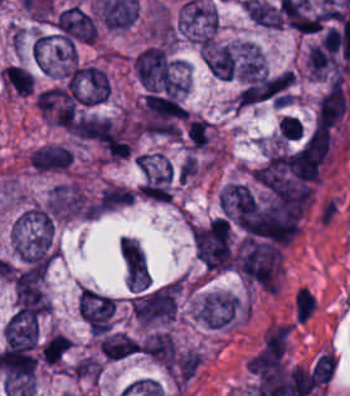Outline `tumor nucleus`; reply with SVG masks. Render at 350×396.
<instances>
[{"label":"tumor nucleus","instance_id":"obj_1","mask_svg":"<svg viewBox=\"0 0 350 396\" xmlns=\"http://www.w3.org/2000/svg\"><path fill=\"white\" fill-rule=\"evenodd\" d=\"M12 247L19 263L30 271H47L55 257L53 222L46 210L30 205L12 227Z\"/></svg>","mask_w":350,"mask_h":396},{"label":"tumor nucleus","instance_id":"obj_8","mask_svg":"<svg viewBox=\"0 0 350 396\" xmlns=\"http://www.w3.org/2000/svg\"><path fill=\"white\" fill-rule=\"evenodd\" d=\"M265 59L258 44L254 41H240L238 77L241 81L251 82L264 75Z\"/></svg>","mask_w":350,"mask_h":396},{"label":"tumor nucleus","instance_id":"obj_5","mask_svg":"<svg viewBox=\"0 0 350 396\" xmlns=\"http://www.w3.org/2000/svg\"><path fill=\"white\" fill-rule=\"evenodd\" d=\"M71 148L57 143H43L27 155V162L38 173H57L71 168Z\"/></svg>","mask_w":350,"mask_h":396},{"label":"tumor nucleus","instance_id":"obj_2","mask_svg":"<svg viewBox=\"0 0 350 396\" xmlns=\"http://www.w3.org/2000/svg\"><path fill=\"white\" fill-rule=\"evenodd\" d=\"M81 134L104 158L120 160L130 154L126 128L121 123L86 117L82 122Z\"/></svg>","mask_w":350,"mask_h":396},{"label":"tumor nucleus","instance_id":"obj_3","mask_svg":"<svg viewBox=\"0 0 350 396\" xmlns=\"http://www.w3.org/2000/svg\"><path fill=\"white\" fill-rule=\"evenodd\" d=\"M239 311V299L235 294L210 291L197 301L193 315L207 329H226Z\"/></svg>","mask_w":350,"mask_h":396},{"label":"tumor nucleus","instance_id":"obj_7","mask_svg":"<svg viewBox=\"0 0 350 396\" xmlns=\"http://www.w3.org/2000/svg\"><path fill=\"white\" fill-rule=\"evenodd\" d=\"M144 354L168 372L177 360V349L172 335L155 332L140 345Z\"/></svg>","mask_w":350,"mask_h":396},{"label":"tumor nucleus","instance_id":"obj_4","mask_svg":"<svg viewBox=\"0 0 350 396\" xmlns=\"http://www.w3.org/2000/svg\"><path fill=\"white\" fill-rule=\"evenodd\" d=\"M78 299L81 315L91 334H105L110 330L115 314L111 296L82 287Z\"/></svg>","mask_w":350,"mask_h":396},{"label":"tumor nucleus","instance_id":"obj_10","mask_svg":"<svg viewBox=\"0 0 350 396\" xmlns=\"http://www.w3.org/2000/svg\"><path fill=\"white\" fill-rule=\"evenodd\" d=\"M118 246L129 272H145V256L134 239L120 237Z\"/></svg>","mask_w":350,"mask_h":396},{"label":"tumor nucleus","instance_id":"obj_9","mask_svg":"<svg viewBox=\"0 0 350 396\" xmlns=\"http://www.w3.org/2000/svg\"><path fill=\"white\" fill-rule=\"evenodd\" d=\"M99 352L110 360H119L139 353L137 341L122 332L106 334L99 338Z\"/></svg>","mask_w":350,"mask_h":396},{"label":"tumor nucleus","instance_id":"obj_6","mask_svg":"<svg viewBox=\"0 0 350 396\" xmlns=\"http://www.w3.org/2000/svg\"><path fill=\"white\" fill-rule=\"evenodd\" d=\"M202 60L210 74L219 80H233L235 59L227 45L209 42L203 45Z\"/></svg>","mask_w":350,"mask_h":396}]
</instances>
